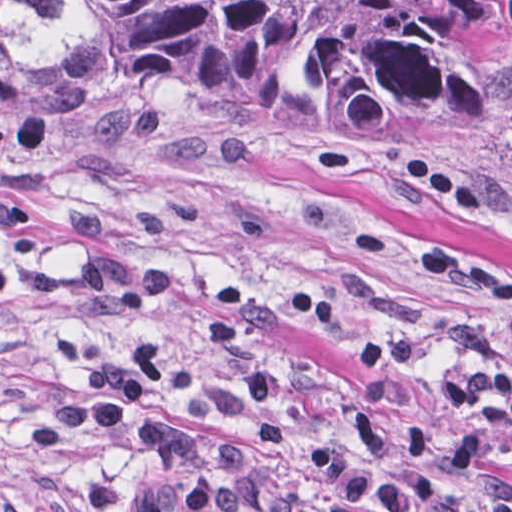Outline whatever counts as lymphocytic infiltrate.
Returning <instances> with one entry per match:
<instances>
[{"label":"lymphocytic infiltrate","instance_id":"1","mask_svg":"<svg viewBox=\"0 0 512 512\" xmlns=\"http://www.w3.org/2000/svg\"><path fill=\"white\" fill-rule=\"evenodd\" d=\"M395 170L401 182L463 216L484 213L468 188L432 163L400 153ZM60 238L71 268L25 265L0 253V288L131 319L140 341L113 352L75 332L51 334L52 354L81 370L83 383L74 399L47 406L24 424L23 442L33 455L69 434L131 438L144 453L146 473L128 512H512L509 488L481 473L500 466L512 478V368L440 376L439 397L463 412L458 462L438 457L428 425L418 422L404 425L396 452L370 407L356 405L345 420L342 447L313 438L293 469L268 470L236 451L202 465L196 440L205 426L275 443L289 439L286 386L271 345L256 330L247 290L216 284L200 335L206 354L236 378L186 381L182 412H170L153 403L176 362L164 323L180 298V270L125 255L95 207L65 213ZM421 268L512 326V278L502 271L441 246L421 252ZM114 510L109 479L95 478L74 496L52 498L32 512Z\"/></svg>","mask_w":512,"mask_h":512}]
</instances>
